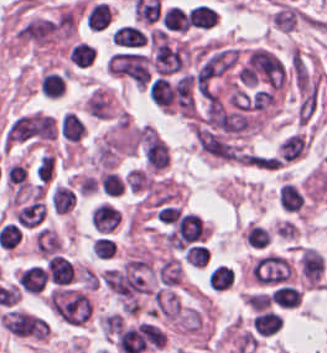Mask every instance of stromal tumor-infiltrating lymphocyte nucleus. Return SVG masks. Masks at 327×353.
<instances>
[{
  "label": "stromal tumor-infiltrating lymphocyte nucleus",
  "mask_w": 327,
  "mask_h": 353,
  "mask_svg": "<svg viewBox=\"0 0 327 353\" xmlns=\"http://www.w3.org/2000/svg\"><path fill=\"white\" fill-rule=\"evenodd\" d=\"M0 324L10 335L22 339L42 340L48 336L47 321L20 308H6L0 316Z\"/></svg>",
  "instance_id": "1"
},
{
  "label": "stromal tumor-infiltrating lymphocyte nucleus",
  "mask_w": 327,
  "mask_h": 353,
  "mask_svg": "<svg viewBox=\"0 0 327 353\" xmlns=\"http://www.w3.org/2000/svg\"><path fill=\"white\" fill-rule=\"evenodd\" d=\"M108 74L135 86L148 81V58L135 51H115L105 65Z\"/></svg>",
  "instance_id": "2"
},
{
  "label": "stromal tumor-infiltrating lymphocyte nucleus",
  "mask_w": 327,
  "mask_h": 353,
  "mask_svg": "<svg viewBox=\"0 0 327 353\" xmlns=\"http://www.w3.org/2000/svg\"><path fill=\"white\" fill-rule=\"evenodd\" d=\"M88 221L94 235L109 234L121 222L120 210L114 202L102 200L88 212Z\"/></svg>",
  "instance_id": "3"
},
{
  "label": "stromal tumor-infiltrating lymphocyte nucleus",
  "mask_w": 327,
  "mask_h": 353,
  "mask_svg": "<svg viewBox=\"0 0 327 353\" xmlns=\"http://www.w3.org/2000/svg\"><path fill=\"white\" fill-rule=\"evenodd\" d=\"M46 282V270L38 262L22 267L15 277L18 290L33 296L42 293Z\"/></svg>",
  "instance_id": "4"
},
{
  "label": "stromal tumor-infiltrating lymphocyte nucleus",
  "mask_w": 327,
  "mask_h": 353,
  "mask_svg": "<svg viewBox=\"0 0 327 353\" xmlns=\"http://www.w3.org/2000/svg\"><path fill=\"white\" fill-rule=\"evenodd\" d=\"M32 248L36 255L47 258L62 251V244L57 231L40 226L33 230Z\"/></svg>",
  "instance_id": "5"
},
{
  "label": "stromal tumor-infiltrating lymphocyte nucleus",
  "mask_w": 327,
  "mask_h": 353,
  "mask_svg": "<svg viewBox=\"0 0 327 353\" xmlns=\"http://www.w3.org/2000/svg\"><path fill=\"white\" fill-rule=\"evenodd\" d=\"M277 203L281 211L299 214L305 209L306 198L301 188L290 182H283L277 193Z\"/></svg>",
  "instance_id": "6"
},
{
  "label": "stromal tumor-infiltrating lymphocyte nucleus",
  "mask_w": 327,
  "mask_h": 353,
  "mask_svg": "<svg viewBox=\"0 0 327 353\" xmlns=\"http://www.w3.org/2000/svg\"><path fill=\"white\" fill-rule=\"evenodd\" d=\"M48 200L52 211L56 215H67L75 207L77 193L67 184L53 185Z\"/></svg>",
  "instance_id": "7"
},
{
  "label": "stromal tumor-infiltrating lymphocyte nucleus",
  "mask_w": 327,
  "mask_h": 353,
  "mask_svg": "<svg viewBox=\"0 0 327 353\" xmlns=\"http://www.w3.org/2000/svg\"><path fill=\"white\" fill-rule=\"evenodd\" d=\"M299 267L309 284H318L325 267L322 256L311 247H304L299 261Z\"/></svg>",
  "instance_id": "8"
},
{
  "label": "stromal tumor-infiltrating lymphocyte nucleus",
  "mask_w": 327,
  "mask_h": 353,
  "mask_svg": "<svg viewBox=\"0 0 327 353\" xmlns=\"http://www.w3.org/2000/svg\"><path fill=\"white\" fill-rule=\"evenodd\" d=\"M111 9L102 2L90 3L83 9V24L90 30H104L110 25Z\"/></svg>",
  "instance_id": "9"
},
{
  "label": "stromal tumor-infiltrating lymphocyte nucleus",
  "mask_w": 327,
  "mask_h": 353,
  "mask_svg": "<svg viewBox=\"0 0 327 353\" xmlns=\"http://www.w3.org/2000/svg\"><path fill=\"white\" fill-rule=\"evenodd\" d=\"M180 276V262L173 256H166L155 266V278L160 287H173Z\"/></svg>",
  "instance_id": "10"
},
{
  "label": "stromal tumor-infiltrating lymphocyte nucleus",
  "mask_w": 327,
  "mask_h": 353,
  "mask_svg": "<svg viewBox=\"0 0 327 353\" xmlns=\"http://www.w3.org/2000/svg\"><path fill=\"white\" fill-rule=\"evenodd\" d=\"M235 280V272L230 265L216 263L207 271L208 287L216 291L228 289Z\"/></svg>",
  "instance_id": "11"
},
{
  "label": "stromal tumor-infiltrating lymphocyte nucleus",
  "mask_w": 327,
  "mask_h": 353,
  "mask_svg": "<svg viewBox=\"0 0 327 353\" xmlns=\"http://www.w3.org/2000/svg\"><path fill=\"white\" fill-rule=\"evenodd\" d=\"M145 40L141 29L130 24L120 25L110 34V41L129 48H139Z\"/></svg>",
  "instance_id": "12"
},
{
  "label": "stromal tumor-infiltrating lymphocyte nucleus",
  "mask_w": 327,
  "mask_h": 353,
  "mask_svg": "<svg viewBox=\"0 0 327 353\" xmlns=\"http://www.w3.org/2000/svg\"><path fill=\"white\" fill-rule=\"evenodd\" d=\"M66 58L69 64L83 69L95 60V49L90 43L77 40L68 46Z\"/></svg>",
  "instance_id": "13"
},
{
  "label": "stromal tumor-infiltrating lymphocyte nucleus",
  "mask_w": 327,
  "mask_h": 353,
  "mask_svg": "<svg viewBox=\"0 0 327 353\" xmlns=\"http://www.w3.org/2000/svg\"><path fill=\"white\" fill-rule=\"evenodd\" d=\"M242 236L248 248L258 251L268 248L271 239L269 229L256 223L245 226Z\"/></svg>",
  "instance_id": "14"
},
{
  "label": "stromal tumor-infiltrating lymphocyte nucleus",
  "mask_w": 327,
  "mask_h": 353,
  "mask_svg": "<svg viewBox=\"0 0 327 353\" xmlns=\"http://www.w3.org/2000/svg\"><path fill=\"white\" fill-rule=\"evenodd\" d=\"M216 17L213 8L197 4L187 12V24L192 28L209 29Z\"/></svg>",
  "instance_id": "15"
},
{
  "label": "stromal tumor-infiltrating lymphocyte nucleus",
  "mask_w": 327,
  "mask_h": 353,
  "mask_svg": "<svg viewBox=\"0 0 327 353\" xmlns=\"http://www.w3.org/2000/svg\"><path fill=\"white\" fill-rule=\"evenodd\" d=\"M58 129L62 137L77 142L83 135L84 127L73 111H66L61 115Z\"/></svg>",
  "instance_id": "16"
},
{
  "label": "stromal tumor-infiltrating lymphocyte nucleus",
  "mask_w": 327,
  "mask_h": 353,
  "mask_svg": "<svg viewBox=\"0 0 327 353\" xmlns=\"http://www.w3.org/2000/svg\"><path fill=\"white\" fill-rule=\"evenodd\" d=\"M269 296L271 302L279 307L294 308L300 303L301 293L295 287L280 285L275 287Z\"/></svg>",
  "instance_id": "17"
},
{
  "label": "stromal tumor-infiltrating lymphocyte nucleus",
  "mask_w": 327,
  "mask_h": 353,
  "mask_svg": "<svg viewBox=\"0 0 327 353\" xmlns=\"http://www.w3.org/2000/svg\"><path fill=\"white\" fill-rule=\"evenodd\" d=\"M38 87L46 97L57 98L63 95V79L54 71H47L40 78Z\"/></svg>",
  "instance_id": "18"
},
{
  "label": "stromal tumor-infiltrating lymphocyte nucleus",
  "mask_w": 327,
  "mask_h": 353,
  "mask_svg": "<svg viewBox=\"0 0 327 353\" xmlns=\"http://www.w3.org/2000/svg\"><path fill=\"white\" fill-rule=\"evenodd\" d=\"M170 31L185 32L189 28L187 13L177 6H170L166 12Z\"/></svg>",
  "instance_id": "19"
},
{
  "label": "stromal tumor-infiltrating lymphocyte nucleus",
  "mask_w": 327,
  "mask_h": 353,
  "mask_svg": "<svg viewBox=\"0 0 327 353\" xmlns=\"http://www.w3.org/2000/svg\"><path fill=\"white\" fill-rule=\"evenodd\" d=\"M98 181L102 193L114 196L121 194V179L116 176L113 172H105L98 178Z\"/></svg>",
  "instance_id": "20"
},
{
  "label": "stromal tumor-infiltrating lymphocyte nucleus",
  "mask_w": 327,
  "mask_h": 353,
  "mask_svg": "<svg viewBox=\"0 0 327 353\" xmlns=\"http://www.w3.org/2000/svg\"><path fill=\"white\" fill-rule=\"evenodd\" d=\"M165 342H166V334L164 335L162 346L165 345Z\"/></svg>",
  "instance_id": "21"
}]
</instances>
